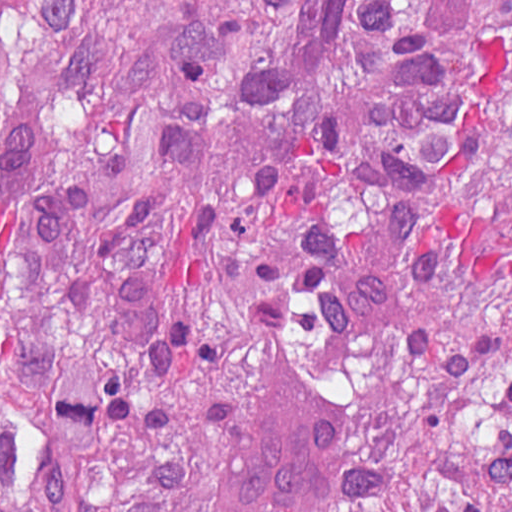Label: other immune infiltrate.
Masks as SVG:
<instances>
[{
    "instance_id": "other-immune-infiltrate-1",
    "label": "other immune infiltrate",
    "mask_w": 512,
    "mask_h": 512,
    "mask_svg": "<svg viewBox=\"0 0 512 512\" xmlns=\"http://www.w3.org/2000/svg\"><path fill=\"white\" fill-rule=\"evenodd\" d=\"M336 442L335 401L285 360L251 385L231 512H315Z\"/></svg>"
}]
</instances>
